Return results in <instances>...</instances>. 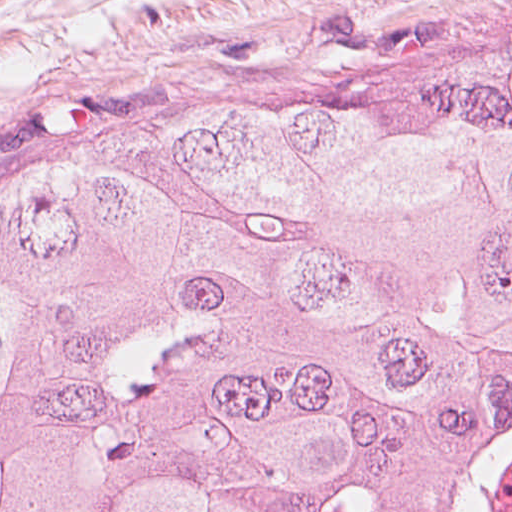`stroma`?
Masks as SVG:
<instances>
[{
	"instance_id": "1",
	"label": "stroma",
	"mask_w": 512,
	"mask_h": 512,
	"mask_svg": "<svg viewBox=\"0 0 512 512\" xmlns=\"http://www.w3.org/2000/svg\"><path fill=\"white\" fill-rule=\"evenodd\" d=\"M512 82V0H0V219L153 144L308 104L391 117Z\"/></svg>"
}]
</instances>
